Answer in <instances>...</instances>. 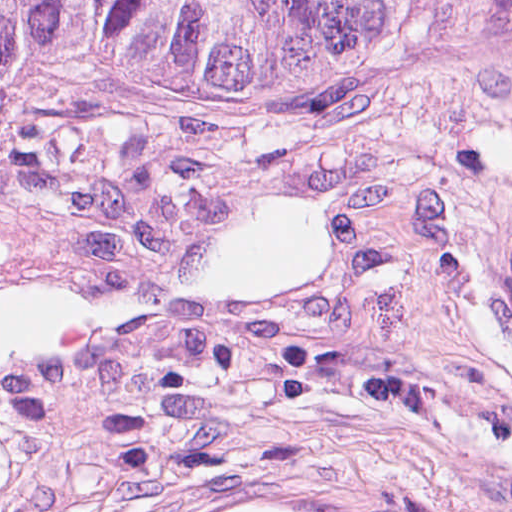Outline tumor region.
Returning a JSON list of instances; mask_svg holds the SVG:
<instances>
[{
  "label": "tumor region",
  "mask_w": 512,
  "mask_h": 512,
  "mask_svg": "<svg viewBox=\"0 0 512 512\" xmlns=\"http://www.w3.org/2000/svg\"><path fill=\"white\" fill-rule=\"evenodd\" d=\"M343 0H0V85H169L220 78ZM465 37L512 65V0H346ZM157 512H407L253 485Z\"/></svg>",
  "instance_id": "obj_1"
}]
</instances>
